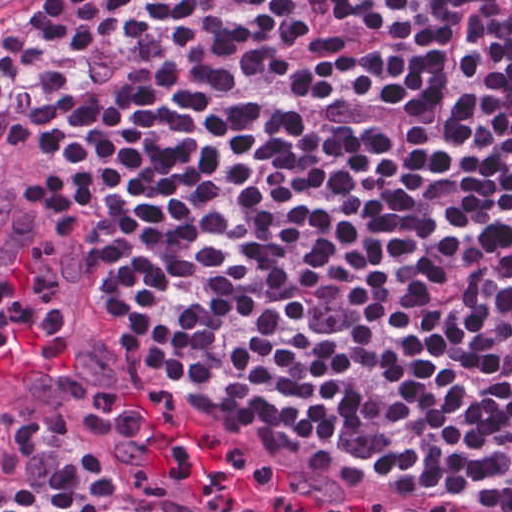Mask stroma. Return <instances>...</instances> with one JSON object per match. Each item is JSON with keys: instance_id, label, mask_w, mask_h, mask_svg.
Here are the masks:
<instances>
[{"instance_id": "1", "label": "stroma", "mask_w": 512, "mask_h": 512, "mask_svg": "<svg viewBox=\"0 0 512 512\" xmlns=\"http://www.w3.org/2000/svg\"><path fill=\"white\" fill-rule=\"evenodd\" d=\"M46 1L30 0L0 21V69L10 62L22 30ZM0 236L54 251L73 270L82 295L86 238L49 194L0 174ZM125 326L101 315L82 297L76 346L40 384L0 390V397L30 412L39 423Z\"/></svg>"}]
</instances>
